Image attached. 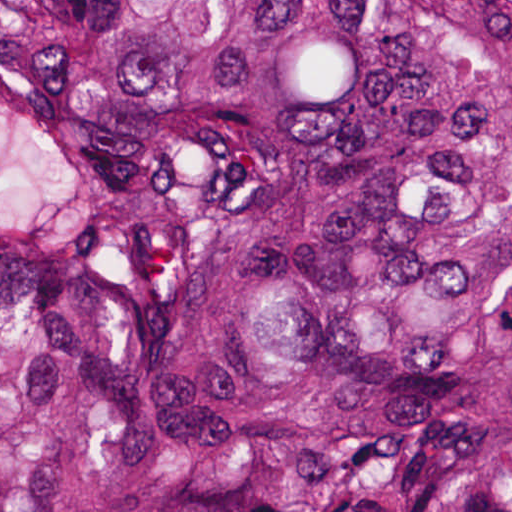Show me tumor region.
Returning <instances> with one entry per match:
<instances>
[{
  "mask_svg": "<svg viewBox=\"0 0 512 512\" xmlns=\"http://www.w3.org/2000/svg\"><path fill=\"white\" fill-rule=\"evenodd\" d=\"M0 512H512V1H0Z\"/></svg>",
  "mask_w": 512,
  "mask_h": 512,
  "instance_id": "e687c5a6",
  "label": "tumor region"
}]
</instances>
